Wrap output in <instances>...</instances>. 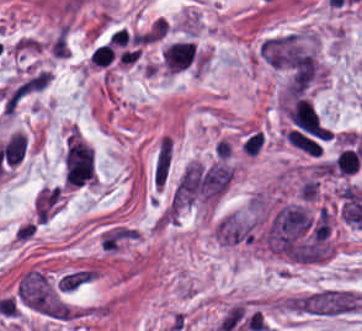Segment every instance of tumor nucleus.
Here are the masks:
<instances>
[{"mask_svg": "<svg viewBox=\"0 0 362 331\" xmlns=\"http://www.w3.org/2000/svg\"><path fill=\"white\" fill-rule=\"evenodd\" d=\"M61 197L62 195L35 217L36 223L53 215L60 202Z\"/></svg>", "mask_w": 362, "mask_h": 331, "instance_id": "obj_1", "label": "tumor nucleus"}]
</instances>
